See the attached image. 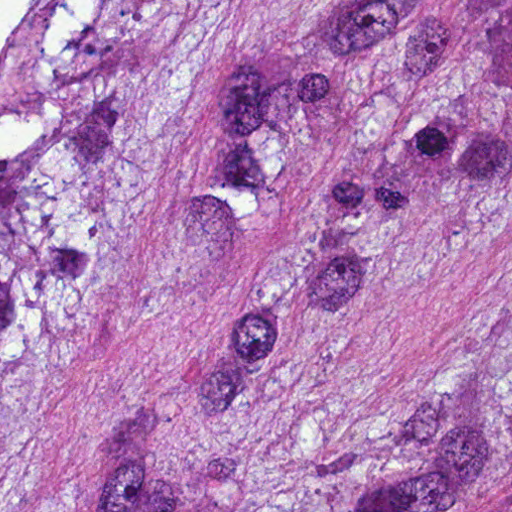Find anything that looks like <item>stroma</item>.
Wrapping results in <instances>:
<instances>
[{"instance_id": "1", "label": "stroma", "mask_w": 512, "mask_h": 512, "mask_svg": "<svg viewBox=\"0 0 512 512\" xmlns=\"http://www.w3.org/2000/svg\"><path fill=\"white\" fill-rule=\"evenodd\" d=\"M350 1L235 0L97 280L22 512H103L149 423L169 420L206 466H243L343 420L429 406L512 344L510 198L331 327L267 398L220 397L217 338L260 253L211 209L225 95Z\"/></svg>"}]
</instances>
